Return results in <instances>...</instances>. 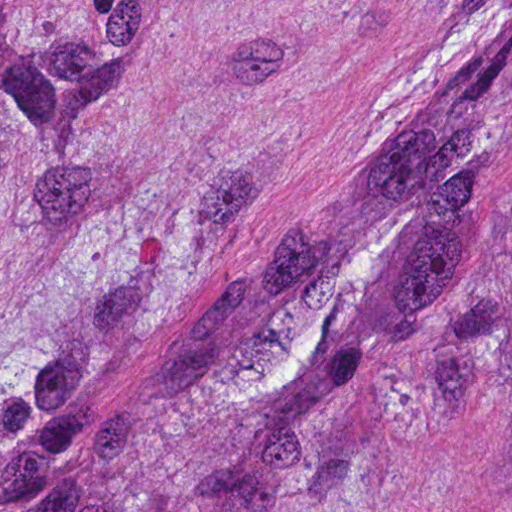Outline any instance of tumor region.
Instances as JSON below:
<instances>
[{
  "label": "tumor region",
  "mask_w": 512,
  "mask_h": 512,
  "mask_svg": "<svg viewBox=\"0 0 512 512\" xmlns=\"http://www.w3.org/2000/svg\"><path fill=\"white\" fill-rule=\"evenodd\" d=\"M125 47L0 2V197ZM0 512H512V49L284 158L164 298L87 246L0 343Z\"/></svg>",
  "instance_id": "e687c5a6"
}]
</instances>
